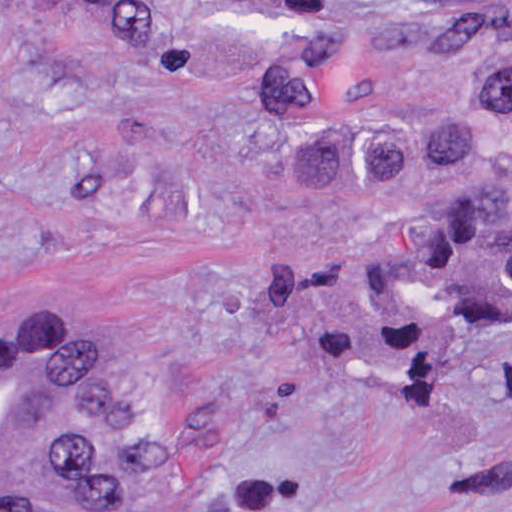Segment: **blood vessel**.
Wrapping results in <instances>:
<instances>
[{
	"mask_svg": "<svg viewBox=\"0 0 512 512\" xmlns=\"http://www.w3.org/2000/svg\"><path fill=\"white\" fill-rule=\"evenodd\" d=\"M122 354V305L99 286L0 339V500L80 457Z\"/></svg>",
	"mask_w": 512,
	"mask_h": 512,
	"instance_id": "blood-vessel-1",
	"label": "blood vessel"
}]
</instances>
